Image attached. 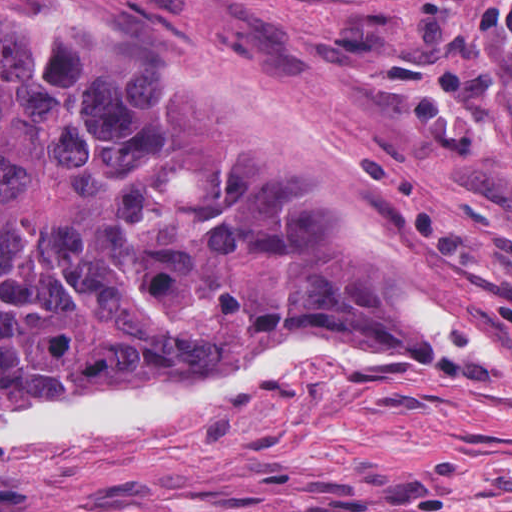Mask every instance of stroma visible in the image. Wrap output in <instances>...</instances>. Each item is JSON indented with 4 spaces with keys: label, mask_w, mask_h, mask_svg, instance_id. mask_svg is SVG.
<instances>
[{
    "label": "stroma",
    "mask_w": 512,
    "mask_h": 512,
    "mask_svg": "<svg viewBox=\"0 0 512 512\" xmlns=\"http://www.w3.org/2000/svg\"><path fill=\"white\" fill-rule=\"evenodd\" d=\"M491 1L0 0L10 48L229 98L313 150L414 307L472 335L320 316L282 347L404 364L0 441V512H512V35L476 29ZM201 382L137 376L0 419Z\"/></svg>",
    "instance_id": "stroma-1"
}]
</instances>
